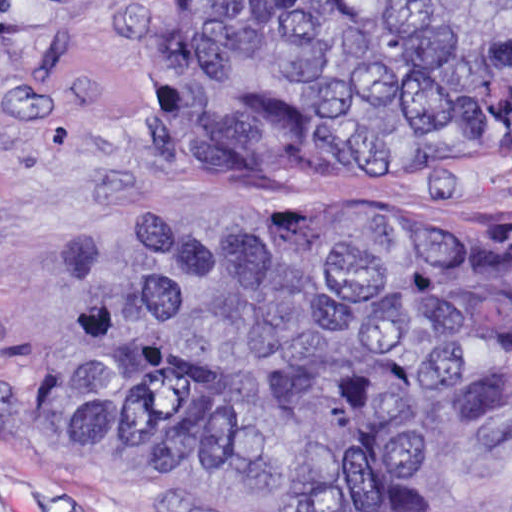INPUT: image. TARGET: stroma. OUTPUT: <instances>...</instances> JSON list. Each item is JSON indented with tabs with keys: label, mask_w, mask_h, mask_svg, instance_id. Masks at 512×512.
<instances>
[{
	"label": "stroma",
	"mask_w": 512,
	"mask_h": 512,
	"mask_svg": "<svg viewBox=\"0 0 512 512\" xmlns=\"http://www.w3.org/2000/svg\"><path fill=\"white\" fill-rule=\"evenodd\" d=\"M213 0H0V512H201L138 469L50 448L32 399L72 365L74 302L167 222L478 233L512 161L412 170L197 165L162 152L159 85ZM420 512H512V449L446 445Z\"/></svg>",
	"instance_id": "stroma-1"
}]
</instances>
